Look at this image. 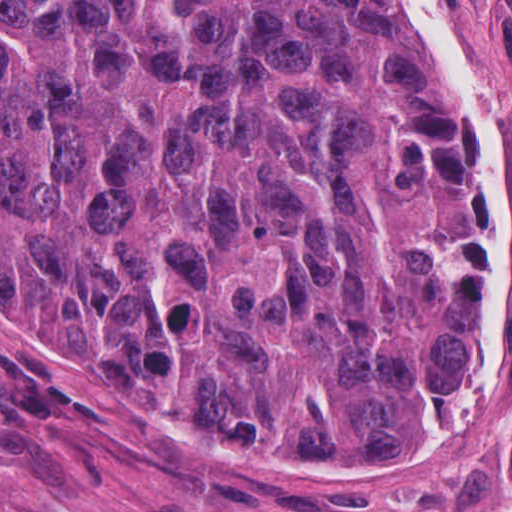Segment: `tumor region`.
Masks as SVG:
<instances>
[{"instance_id":"obj_1","label":"tumor region","mask_w":512,"mask_h":512,"mask_svg":"<svg viewBox=\"0 0 512 512\" xmlns=\"http://www.w3.org/2000/svg\"><path fill=\"white\" fill-rule=\"evenodd\" d=\"M426 60L373 0H0V299L219 447L382 469L501 343Z\"/></svg>"}]
</instances>
